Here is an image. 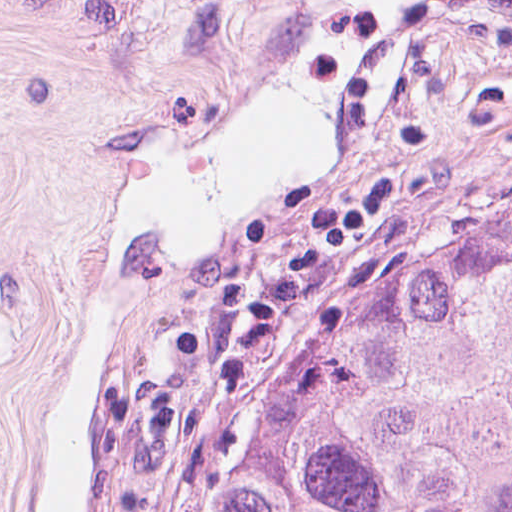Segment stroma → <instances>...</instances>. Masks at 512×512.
I'll use <instances>...</instances> for the list:
<instances>
[{"label": "stroma", "mask_w": 512, "mask_h": 512, "mask_svg": "<svg viewBox=\"0 0 512 512\" xmlns=\"http://www.w3.org/2000/svg\"><path fill=\"white\" fill-rule=\"evenodd\" d=\"M294 0H0V512L38 428L123 155L225 134L285 58ZM512 177V0H397V49L278 222L152 299L105 394L80 512H136L242 328L284 287Z\"/></svg>", "instance_id": "1"}]
</instances>
